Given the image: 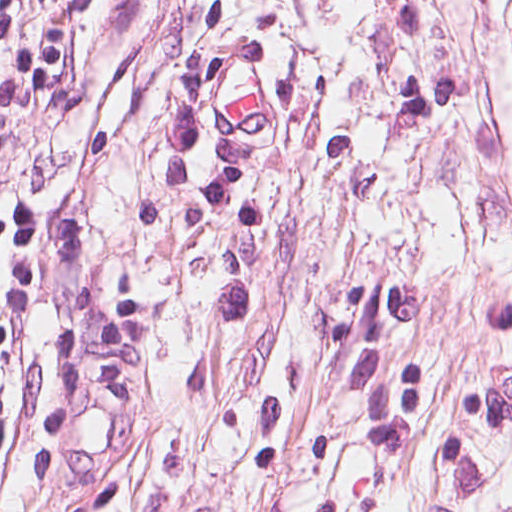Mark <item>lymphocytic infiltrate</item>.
<instances>
[{
  "instance_id": "f902f5d3",
  "label": "lymphocytic infiltrate",
  "mask_w": 512,
  "mask_h": 512,
  "mask_svg": "<svg viewBox=\"0 0 512 512\" xmlns=\"http://www.w3.org/2000/svg\"><path fill=\"white\" fill-rule=\"evenodd\" d=\"M82 71L71 0H0V355L18 296L27 173L73 105Z\"/></svg>"
}]
</instances>
